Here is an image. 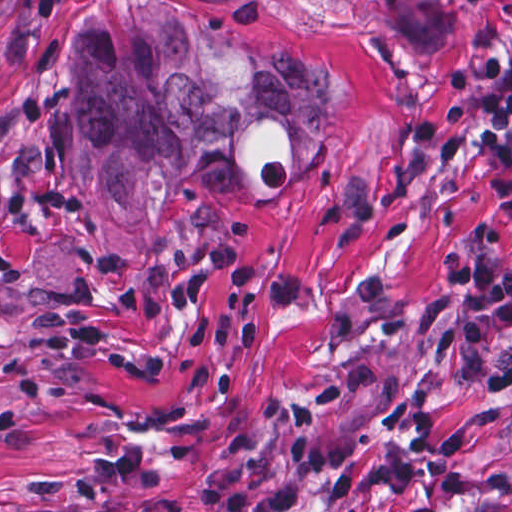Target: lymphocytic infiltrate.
<instances>
[{
	"label": "lymphocytic infiltrate",
	"instance_id": "obj_1",
	"mask_svg": "<svg viewBox=\"0 0 512 512\" xmlns=\"http://www.w3.org/2000/svg\"><path fill=\"white\" fill-rule=\"evenodd\" d=\"M451 95L429 117L410 123L413 150L435 167H446L461 153L467 128L500 155L512 154V69L491 54L463 62L449 77ZM442 273L454 299L459 326L452 359L470 387L485 397H512V266L498 252L446 254ZM379 382L377 365L360 364L338 372L316 392L292 401L287 410L283 461L279 473L259 484L211 476L199 486L192 512H293L310 503L298 491L260 496L262 490L316 482L343 465L355 450L346 437L319 442L327 417L352 396ZM62 512H139L98 498L79 501ZM450 512H475L458 507Z\"/></svg>",
	"mask_w": 512,
	"mask_h": 512
}]
</instances>
